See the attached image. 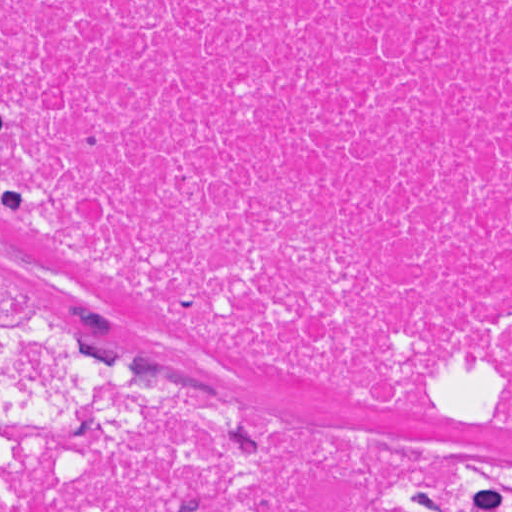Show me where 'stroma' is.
<instances>
[{
    "label": "stroma",
    "instance_id": "stroma-1",
    "mask_svg": "<svg viewBox=\"0 0 512 512\" xmlns=\"http://www.w3.org/2000/svg\"><path fill=\"white\" fill-rule=\"evenodd\" d=\"M0 312L130 344L270 425L437 439L460 459L467 503L483 509L496 468L512 467V425L491 416L503 382L473 384L467 407L452 408L285 371L155 313L100 262L2 208Z\"/></svg>",
    "mask_w": 512,
    "mask_h": 512
}]
</instances>
